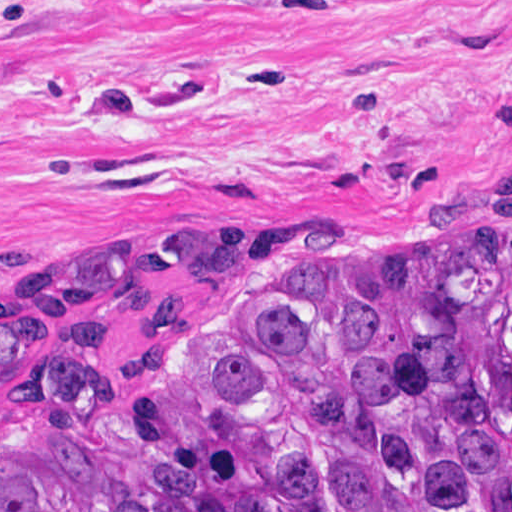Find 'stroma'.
I'll list each match as a JSON object with an SVG mask.
<instances>
[{
  "label": "stroma",
  "mask_w": 512,
  "mask_h": 512,
  "mask_svg": "<svg viewBox=\"0 0 512 512\" xmlns=\"http://www.w3.org/2000/svg\"><path fill=\"white\" fill-rule=\"evenodd\" d=\"M511 181L512 0H0V312Z\"/></svg>",
  "instance_id": "35a3bbf8"
}]
</instances>
